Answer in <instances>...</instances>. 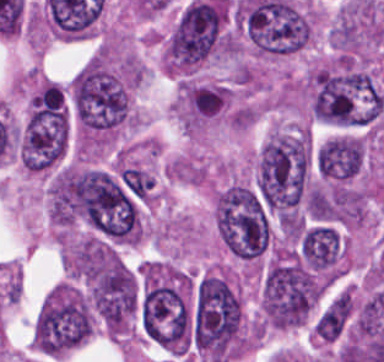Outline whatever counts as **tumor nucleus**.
Returning <instances> with one entry per match:
<instances>
[{
    "label": "tumor nucleus",
    "mask_w": 384,
    "mask_h": 362,
    "mask_svg": "<svg viewBox=\"0 0 384 362\" xmlns=\"http://www.w3.org/2000/svg\"><path fill=\"white\" fill-rule=\"evenodd\" d=\"M191 341L217 362L242 347V303L220 272L207 271L192 285Z\"/></svg>",
    "instance_id": "2f306a5c"
},
{
    "label": "tumor nucleus",
    "mask_w": 384,
    "mask_h": 362,
    "mask_svg": "<svg viewBox=\"0 0 384 362\" xmlns=\"http://www.w3.org/2000/svg\"><path fill=\"white\" fill-rule=\"evenodd\" d=\"M213 219L220 241L234 256L252 260L266 248L267 209L250 186L233 181L221 188L213 204Z\"/></svg>",
    "instance_id": "8643909e"
}]
</instances>
